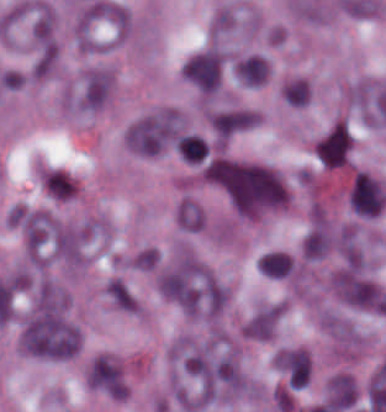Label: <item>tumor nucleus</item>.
I'll return each instance as SVG.
<instances>
[{
    "mask_svg": "<svg viewBox=\"0 0 386 412\" xmlns=\"http://www.w3.org/2000/svg\"><path fill=\"white\" fill-rule=\"evenodd\" d=\"M213 178L240 215H259L287 202L280 173L260 163L216 160Z\"/></svg>",
    "mask_w": 386,
    "mask_h": 412,
    "instance_id": "obj_1",
    "label": "tumor nucleus"
},
{
    "mask_svg": "<svg viewBox=\"0 0 386 412\" xmlns=\"http://www.w3.org/2000/svg\"><path fill=\"white\" fill-rule=\"evenodd\" d=\"M165 293L192 316L216 317L228 291L209 272L200 268H174L165 272Z\"/></svg>",
    "mask_w": 386,
    "mask_h": 412,
    "instance_id": "obj_2",
    "label": "tumor nucleus"
},
{
    "mask_svg": "<svg viewBox=\"0 0 386 412\" xmlns=\"http://www.w3.org/2000/svg\"><path fill=\"white\" fill-rule=\"evenodd\" d=\"M20 341L34 357L66 359L79 349V330L59 311L41 308L26 320Z\"/></svg>",
    "mask_w": 386,
    "mask_h": 412,
    "instance_id": "obj_3",
    "label": "tumor nucleus"
},
{
    "mask_svg": "<svg viewBox=\"0 0 386 412\" xmlns=\"http://www.w3.org/2000/svg\"><path fill=\"white\" fill-rule=\"evenodd\" d=\"M180 133V114L171 108H158L128 122L122 138L134 152L151 156L171 146Z\"/></svg>",
    "mask_w": 386,
    "mask_h": 412,
    "instance_id": "obj_4",
    "label": "tumor nucleus"
},
{
    "mask_svg": "<svg viewBox=\"0 0 386 412\" xmlns=\"http://www.w3.org/2000/svg\"><path fill=\"white\" fill-rule=\"evenodd\" d=\"M350 209L359 215L376 216L386 203L379 184L364 171H356L348 194Z\"/></svg>",
    "mask_w": 386,
    "mask_h": 412,
    "instance_id": "obj_5",
    "label": "tumor nucleus"
},
{
    "mask_svg": "<svg viewBox=\"0 0 386 412\" xmlns=\"http://www.w3.org/2000/svg\"><path fill=\"white\" fill-rule=\"evenodd\" d=\"M220 68L219 53L205 50L188 59L180 72L203 93H214L218 85Z\"/></svg>",
    "mask_w": 386,
    "mask_h": 412,
    "instance_id": "obj_6",
    "label": "tumor nucleus"
},
{
    "mask_svg": "<svg viewBox=\"0 0 386 412\" xmlns=\"http://www.w3.org/2000/svg\"><path fill=\"white\" fill-rule=\"evenodd\" d=\"M36 181L45 197L54 202H69L79 189L71 172L51 164L38 168Z\"/></svg>",
    "mask_w": 386,
    "mask_h": 412,
    "instance_id": "obj_7",
    "label": "tumor nucleus"
},
{
    "mask_svg": "<svg viewBox=\"0 0 386 412\" xmlns=\"http://www.w3.org/2000/svg\"><path fill=\"white\" fill-rule=\"evenodd\" d=\"M57 225L47 214L30 210L22 213L20 227L28 254H42Z\"/></svg>",
    "mask_w": 386,
    "mask_h": 412,
    "instance_id": "obj_8",
    "label": "tumor nucleus"
},
{
    "mask_svg": "<svg viewBox=\"0 0 386 412\" xmlns=\"http://www.w3.org/2000/svg\"><path fill=\"white\" fill-rule=\"evenodd\" d=\"M234 69L244 85L256 86L263 83L269 74L264 58L258 55H250L239 61Z\"/></svg>",
    "mask_w": 386,
    "mask_h": 412,
    "instance_id": "obj_9",
    "label": "tumor nucleus"
},
{
    "mask_svg": "<svg viewBox=\"0 0 386 412\" xmlns=\"http://www.w3.org/2000/svg\"><path fill=\"white\" fill-rule=\"evenodd\" d=\"M329 247V236L323 227L315 226L305 233L301 251L308 259L324 256Z\"/></svg>",
    "mask_w": 386,
    "mask_h": 412,
    "instance_id": "obj_10",
    "label": "tumor nucleus"
},
{
    "mask_svg": "<svg viewBox=\"0 0 386 412\" xmlns=\"http://www.w3.org/2000/svg\"><path fill=\"white\" fill-rule=\"evenodd\" d=\"M175 218L179 227L187 231H198L204 222L202 210L183 198L176 205Z\"/></svg>",
    "mask_w": 386,
    "mask_h": 412,
    "instance_id": "obj_11",
    "label": "tumor nucleus"
},
{
    "mask_svg": "<svg viewBox=\"0 0 386 412\" xmlns=\"http://www.w3.org/2000/svg\"><path fill=\"white\" fill-rule=\"evenodd\" d=\"M56 58V48L48 40L38 46L29 69L33 78H44L52 70Z\"/></svg>",
    "mask_w": 386,
    "mask_h": 412,
    "instance_id": "obj_12",
    "label": "tumor nucleus"
},
{
    "mask_svg": "<svg viewBox=\"0 0 386 412\" xmlns=\"http://www.w3.org/2000/svg\"><path fill=\"white\" fill-rule=\"evenodd\" d=\"M104 292L110 302L120 310L133 311L134 299L126 285L116 277L106 282Z\"/></svg>",
    "mask_w": 386,
    "mask_h": 412,
    "instance_id": "obj_13",
    "label": "tumor nucleus"
},
{
    "mask_svg": "<svg viewBox=\"0 0 386 412\" xmlns=\"http://www.w3.org/2000/svg\"><path fill=\"white\" fill-rule=\"evenodd\" d=\"M282 100L295 106H306L308 104L309 89L305 82L294 79L280 87Z\"/></svg>",
    "mask_w": 386,
    "mask_h": 412,
    "instance_id": "obj_14",
    "label": "tumor nucleus"
}]
</instances>
